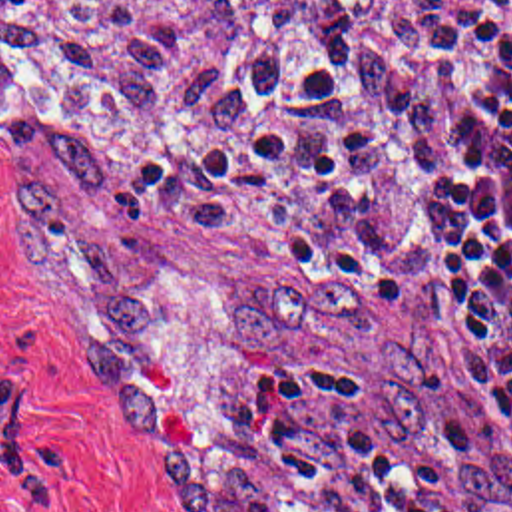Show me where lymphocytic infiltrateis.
Segmentation results:
<instances>
[{
	"label": "lymphocytic infiltrate",
	"instance_id": "1",
	"mask_svg": "<svg viewBox=\"0 0 512 512\" xmlns=\"http://www.w3.org/2000/svg\"><path fill=\"white\" fill-rule=\"evenodd\" d=\"M426 155L439 300L512 448V3L461 35L433 83ZM149 466L175 512H441L314 360L268 370Z\"/></svg>",
	"mask_w": 512,
	"mask_h": 512
}]
</instances>
